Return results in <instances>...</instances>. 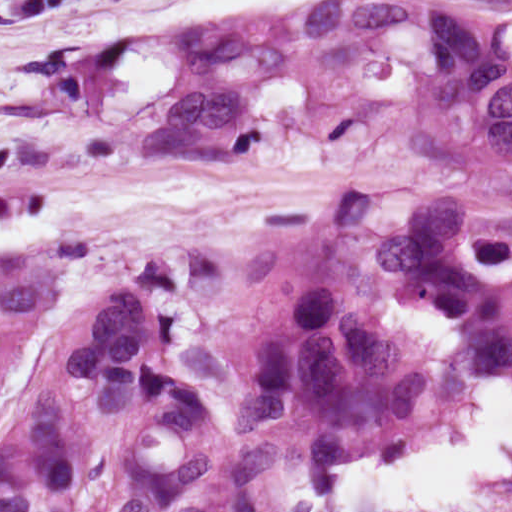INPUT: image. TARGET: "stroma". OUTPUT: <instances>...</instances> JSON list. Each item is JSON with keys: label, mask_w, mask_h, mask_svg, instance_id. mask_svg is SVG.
I'll return each instance as SVG.
<instances>
[{"label": "stroma", "mask_w": 512, "mask_h": 512, "mask_svg": "<svg viewBox=\"0 0 512 512\" xmlns=\"http://www.w3.org/2000/svg\"><path fill=\"white\" fill-rule=\"evenodd\" d=\"M477 383L456 369L276 449L284 501L296 497L294 482L327 473L340 459L414 448L451 434L463 421L467 387Z\"/></svg>", "instance_id": "1"}]
</instances>
